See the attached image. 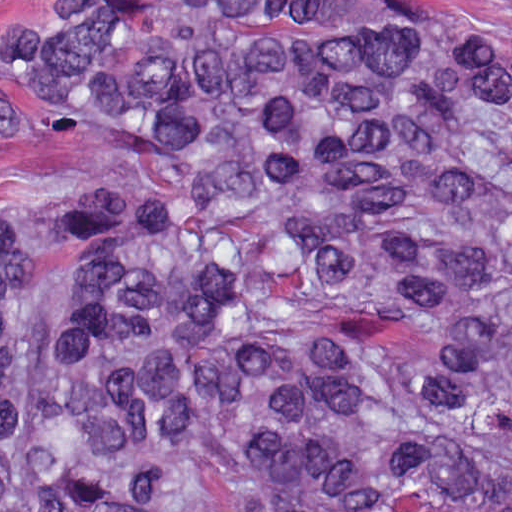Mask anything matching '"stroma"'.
<instances>
[{
	"instance_id": "35a3bbf8",
	"label": "stroma",
	"mask_w": 512,
	"mask_h": 512,
	"mask_svg": "<svg viewBox=\"0 0 512 512\" xmlns=\"http://www.w3.org/2000/svg\"><path fill=\"white\" fill-rule=\"evenodd\" d=\"M22 0H0V21ZM475 14L512 11V0H462ZM15 70L0 46V93L18 119L16 135L0 141V183L3 177H70L86 165V153L73 140L57 136L36 99L11 72ZM0 512H25L0 500Z\"/></svg>"
}]
</instances>
